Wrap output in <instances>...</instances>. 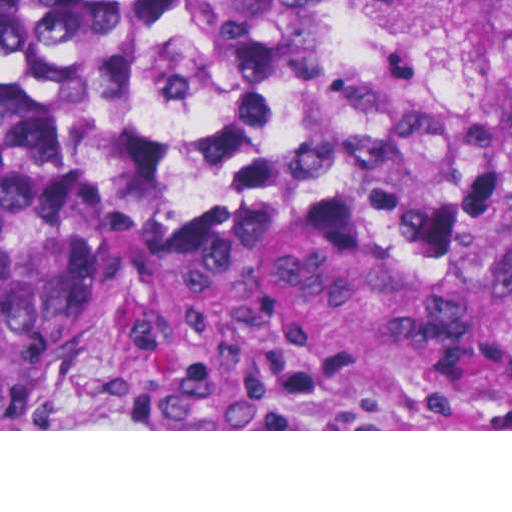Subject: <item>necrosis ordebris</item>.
I'll return each instance as SVG.
<instances>
[{
	"mask_svg": "<svg viewBox=\"0 0 512 512\" xmlns=\"http://www.w3.org/2000/svg\"><path fill=\"white\" fill-rule=\"evenodd\" d=\"M512 114V0H426L392 48L326 83L238 99H178L109 131L122 221L148 228L205 164L272 145H362L426 154L459 124Z\"/></svg>",
	"mask_w": 512,
	"mask_h": 512,
	"instance_id": "1",
	"label": "necrosis or debris"
}]
</instances>
